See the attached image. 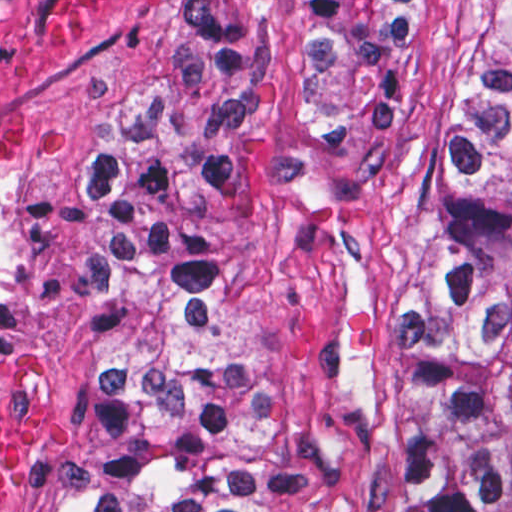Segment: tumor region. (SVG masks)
<instances>
[{"label": "tumor region", "mask_w": 512, "mask_h": 512, "mask_svg": "<svg viewBox=\"0 0 512 512\" xmlns=\"http://www.w3.org/2000/svg\"><path fill=\"white\" fill-rule=\"evenodd\" d=\"M429 49L430 1H188L187 60L78 167L100 318L62 512H261L223 194L270 168L333 179ZM371 412L393 512H512V1H482Z\"/></svg>", "instance_id": "obj_1"}]
</instances>
